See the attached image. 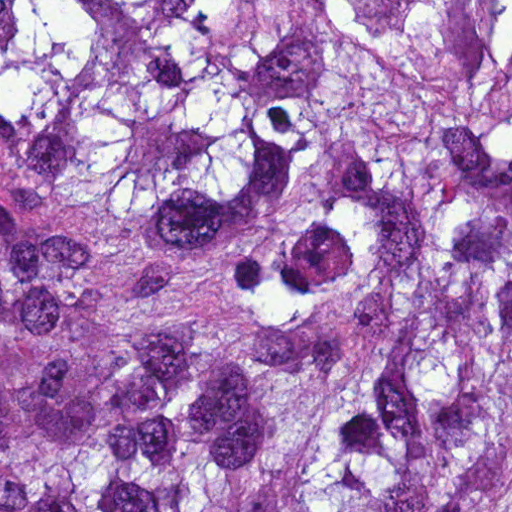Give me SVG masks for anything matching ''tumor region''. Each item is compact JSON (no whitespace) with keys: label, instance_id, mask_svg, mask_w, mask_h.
Listing matches in <instances>:
<instances>
[{"label":"tumor region","instance_id":"e687c5a6","mask_svg":"<svg viewBox=\"0 0 512 512\" xmlns=\"http://www.w3.org/2000/svg\"><path fill=\"white\" fill-rule=\"evenodd\" d=\"M0 512H512V0H0Z\"/></svg>","mask_w":512,"mask_h":512}]
</instances>
